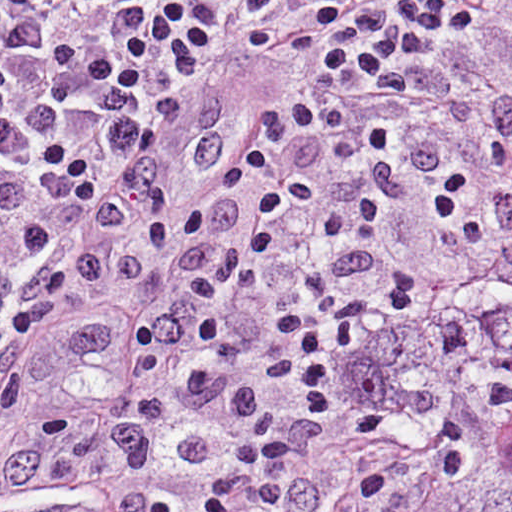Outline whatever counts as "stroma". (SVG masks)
<instances>
[{
	"mask_svg": "<svg viewBox=\"0 0 512 512\" xmlns=\"http://www.w3.org/2000/svg\"><path fill=\"white\" fill-rule=\"evenodd\" d=\"M468 50L438 38L410 81L405 126L438 141L436 165L401 208L383 242L387 257L453 289L490 257L440 228L435 198L455 171L477 169L494 218L512 214L495 136L497 107L512 100V0H477ZM195 95L224 101L225 149L195 166L189 116L174 125L164 190L179 237L207 193L245 158L268 117L308 91V59L263 55L238 26L227 28L191 75ZM0 512H141L119 429L87 380L37 332L0 320Z\"/></svg>",
	"mask_w": 512,
	"mask_h": 512,
	"instance_id": "obj_1",
	"label": "stroma"
}]
</instances>
